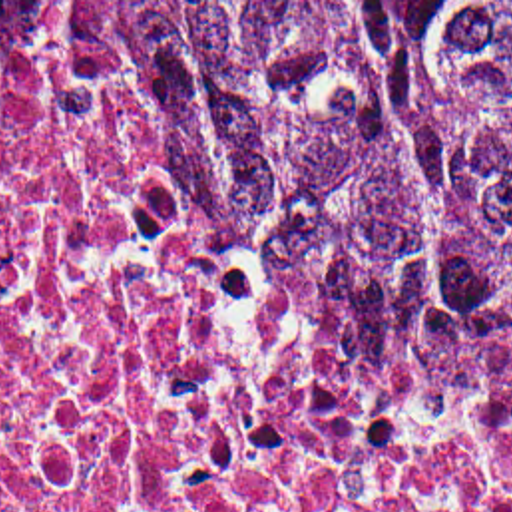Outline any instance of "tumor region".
<instances>
[{"instance_id": "obj_1", "label": "tumor region", "mask_w": 512, "mask_h": 512, "mask_svg": "<svg viewBox=\"0 0 512 512\" xmlns=\"http://www.w3.org/2000/svg\"><path fill=\"white\" fill-rule=\"evenodd\" d=\"M0 30L135 38L399 360L512 392V2H0Z\"/></svg>"}]
</instances>
